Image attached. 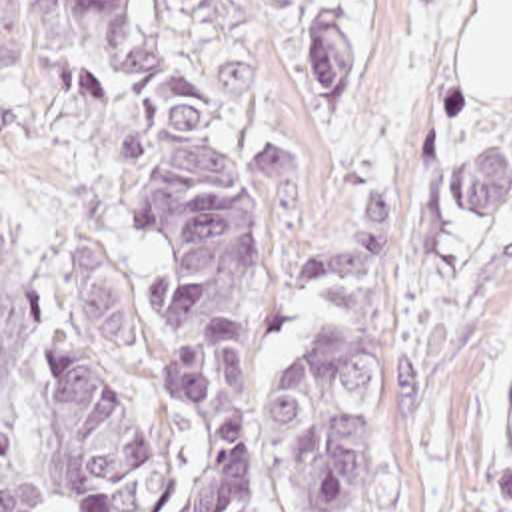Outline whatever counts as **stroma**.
<instances>
[{"mask_svg":"<svg viewBox=\"0 0 512 512\" xmlns=\"http://www.w3.org/2000/svg\"><path fill=\"white\" fill-rule=\"evenodd\" d=\"M481 0H244L258 133H293L297 203L270 249L273 281L345 241L385 189V387L355 460L349 512H501L512 385V99H475L461 71ZM353 33V75L323 123L307 27ZM473 147L511 157L481 217L447 201ZM283 377L343 317L327 285L275 299Z\"/></svg>","mask_w":512,"mask_h":512,"instance_id":"obj_1","label":"stroma"}]
</instances>
